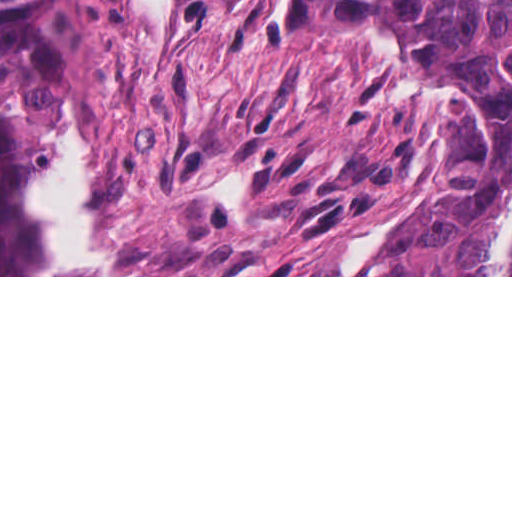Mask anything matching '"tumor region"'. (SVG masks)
I'll use <instances>...</instances> for the list:
<instances>
[{
  "mask_svg": "<svg viewBox=\"0 0 512 512\" xmlns=\"http://www.w3.org/2000/svg\"><path fill=\"white\" fill-rule=\"evenodd\" d=\"M309 1L360 30L445 47L482 63L505 125L500 163L457 183L411 238L367 275H494L498 234L512 199V0Z\"/></svg>",
  "mask_w": 512,
  "mask_h": 512,
  "instance_id": "e687c5a6",
  "label": "tumor region"
}]
</instances>
